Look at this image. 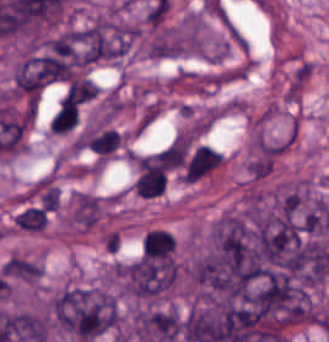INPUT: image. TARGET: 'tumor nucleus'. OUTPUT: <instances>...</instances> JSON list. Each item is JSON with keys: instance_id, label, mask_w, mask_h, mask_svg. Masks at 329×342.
I'll return each mask as SVG.
<instances>
[{"instance_id": "obj_2", "label": "tumor nucleus", "mask_w": 329, "mask_h": 342, "mask_svg": "<svg viewBox=\"0 0 329 342\" xmlns=\"http://www.w3.org/2000/svg\"><path fill=\"white\" fill-rule=\"evenodd\" d=\"M49 315L60 330L87 342L112 328L115 295L101 284H68L52 296Z\"/></svg>"}, {"instance_id": "obj_1", "label": "tumor nucleus", "mask_w": 329, "mask_h": 342, "mask_svg": "<svg viewBox=\"0 0 329 342\" xmlns=\"http://www.w3.org/2000/svg\"><path fill=\"white\" fill-rule=\"evenodd\" d=\"M178 281L175 253L138 255L119 264V287L133 330L172 295Z\"/></svg>"}]
</instances>
